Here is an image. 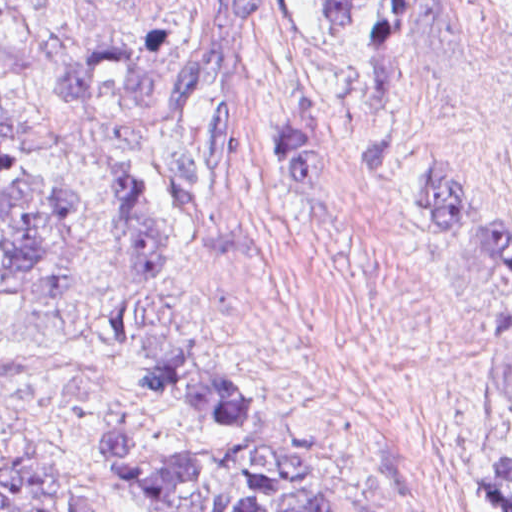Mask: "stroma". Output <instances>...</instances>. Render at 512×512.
<instances>
[{"label": "stroma", "instance_id": "obj_1", "mask_svg": "<svg viewBox=\"0 0 512 512\" xmlns=\"http://www.w3.org/2000/svg\"><path fill=\"white\" fill-rule=\"evenodd\" d=\"M381 2L386 39L366 58L328 57L292 0H263L240 27L232 148L255 248L221 255L185 235L165 193L128 285L42 296L0 328V499L43 482L83 512H147L114 475L104 421L132 400L141 359L192 344L269 395L278 433L347 512H495L478 476L512 385V274L446 247L418 168L446 165L512 231V0ZM195 18L194 0H0V132L102 133L152 167L177 113L57 98L52 76L87 40L135 49L144 26ZM287 94L322 96L326 193L280 172Z\"/></svg>", "mask_w": 512, "mask_h": 512}]
</instances>
